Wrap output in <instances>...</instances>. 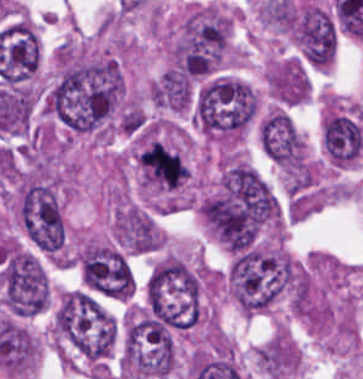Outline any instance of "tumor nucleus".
<instances>
[{
    "mask_svg": "<svg viewBox=\"0 0 363 379\" xmlns=\"http://www.w3.org/2000/svg\"><path fill=\"white\" fill-rule=\"evenodd\" d=\"M289 23L300 59L316 69L329 67L337 52V28L332 14L304 0L293 8Z\"/></svg>",
    "mask_w": 363,
    "mask_h": 379,
    "instance_id": "2f306a5c",
    "label": "tumor nucleus"
},
{
    "mask_svg": "<svg viewBox=\"0 0 363 379\" xmlns=\"http://www.w3.org/2000/svg\"><path fill=\"white\" fill-rule=\"evenodd\" d=\"M259 141L270 158H303V139L287 112L273 110L259 123Z\"/></svg>",
    "mask_w": 363,
    "mask_h": 379,
    "instance_id": "8643909e",
    "label": "tumor nucleus"
}]
</instances>
